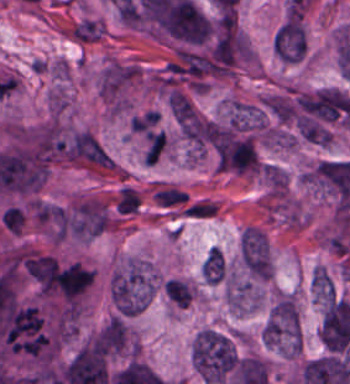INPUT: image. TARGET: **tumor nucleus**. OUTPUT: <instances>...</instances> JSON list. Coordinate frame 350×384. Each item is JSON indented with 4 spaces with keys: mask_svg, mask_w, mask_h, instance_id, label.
Listing matches in <instances>:
<instances>
[{
    "mask_svg": "<svg viewBox=\"0 0 350 384\" xmlns=\"http://www.w3.org/2000/svg\"><path fill=\"white\" fill-rule=\"evenodd\" d=\"M273 49L279 60L298 64L307 52L303 19L300 14L287 17L273 36Z\"/></svg>",
    "mask_w": 350,
    "mask_h": 384,
    "instance_id": "3d1891a8",
    "label": "tumor nucleus"
},
{
    "mask_svg": "<svg viewBox=\"0 0 350 384\" xmlns=\"http://www.w3.org/2000/svg\"><path fill=\"white\" fill-rule=\"evenodd\" d=\"M110 225L111 217L107 208L92 199L70 205L64 215V234L74 239L91 240Z\"/></svg>",
    "mask_w": 350,
    "mask_h": 384,
    "instance_id": "2cbd58db",
    "label": "tumor nucleus"
},
{
    "mask_svg": "<svg viewBox=\"0 0 350 384\" xmlns=\"http://www.w3.org/2000/svg\"><path fill=\"white\" fill-rule=\"evenodd\" d=\"M154 287L152 271L138 260H131L113 271L108 290L118 314L132 315L147 306Z\"/></svg>",
    "mask_w": 350,
    "mask_h": 384,
    "instance_id": "8643909e",
    "label": "tumor nucleus"
},
{
    "mask_svg": "<svg viewBox=\"0 0 350 384\" xmlns=\"http://www.w3.org/2000/svg\"><path fill=\"white\" fill-rule=\"evenodd\" d=\"M206 283L220 284L225 281L227 263L225 255L211 247L200 269Z\"/></svg>",
    "mask_w": 350,
    "mask_h": 384,
    "instance_id": "8087334f",
    "label": "tumor nucleus"
},
{
    "mask_svg": "<svg viewBox=\"0 0 350 384\" xmlns=\"http://www.w3.org/2000/svg\"><path fill=\"white\" fill-rule=\"evenodd\" d=\"M240 360L233 339L221 329L205 327L195 336L193 364L208 384H220L236 369Z\"/></svg>",
    "mask_w": 350,
    "mask_h": 384,
    "instance_id": "2f306a5c",
    "label": "tumor nucleus"
},
{
    "mask_svg": "<svg viewBox=\"0 0 350 384\" xmlns=\"http://www.w3.org/2000/svg\"><path fill=\"white\" fill-rule=\"evenodd\" d=\"M89 341L105 355L115 358L134 348L127 319L117 314L108 318Z\"/></svg>",
    "mask_w": 350,
    "mask_h": 384,
    "instance_id": "2083b535",
    "label": "tumor nucleus"
},
{
    "mask_svg": "<svg viewBox=\"0 0 350 384\" xmlns=\"http://www.w3.org/2000/svg\"><path fill=\"white\" fill-rule=\"evenodd\" d=\"M263 341L294 354L302 345V325L296 300L289 293L278 297L263 325Z\"/></svg>",
    "mask_w": 350,
    "mask_h": 384,
    "instance_id": "5ab6c2c4",
    "label": "tumor nucleus"
},
{
    "mask_svg": "<svg viewBox=\"0 0 350 384\" xmlns=\"http://www.w3.org/2000/svg\"><path fill=\"white\" fill-rule=\"evenodd\" d=\"M172 305L177 308H187L194 297V292L183 278H169L163 286Z\"/></svg>",
    "mask_w": 350,
    "mask_h": 384,
    "instance_id": "c2bd9aea",
    "label": "tumor nucleus"
}]
</instances>
